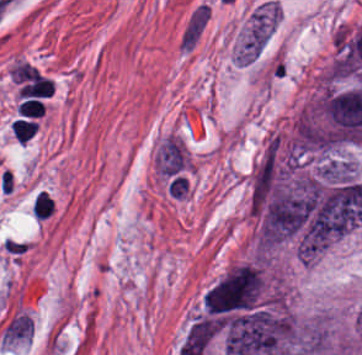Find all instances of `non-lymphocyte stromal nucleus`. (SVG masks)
Returning <instances> with one entry per match:
<instances>
[{"label": "non-lymphocyte stromal nucleus", "instance_id": "non-lymphocyte-stromal-nucleus-2", "mask_svg": "<svg viewBox=\"0 0 362 355\" xmlns=\"http://www.w3.org/2000/svg\"><path fill=\"white\" fill-rule=\"evenodd\" d=\"M211 16L208 2H200L194 6L179 34L178 48L182 53H190L200 41Z\"/></svg>", "mask_w": 362, "mask_h": 355}, {"label": "non-lymphocyte stromal nucleus", "instance_id": "non-lymphocyte-stromal-nucleus-1", "mask_svg": "<svg viewBox=\"0 0 362 355\" xmlns=\"http://www.w3.org/2000/svg\"><path fill=\"white\" fill-rule=\"evenodd\" d=\"M272 14L273 10L266 7L249 21L239 44V63L256 61L269 40Z\"/></svg>", "mask_w": 362, "mask_h": 355}, {"label": "non-lymphocyte stromal nucleus", "instance_id": "non-lymphocyte-stromal-nucleus-3", "mask_svg": "<svg viewBox=\"0 0 362 355\" xmlns=\"http://www.w3.org/2000/svg\"><path fill=\"white\" fill-rule=\"evenodd\" d=\"M252 35L266 37L280 19V8L272 0H265L250 14Z\"/></svg>", "mask_w": 362, "mask_h": 355}]
</instances>
